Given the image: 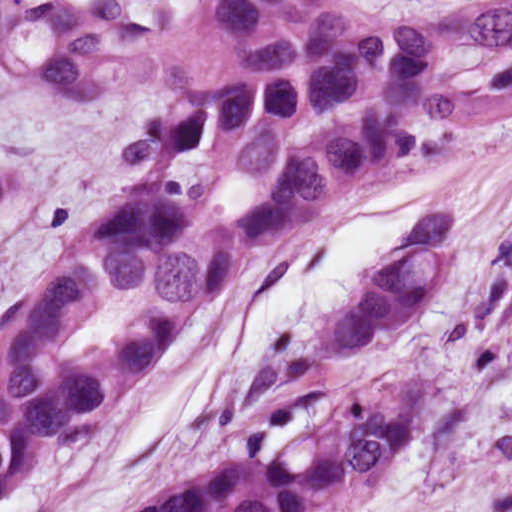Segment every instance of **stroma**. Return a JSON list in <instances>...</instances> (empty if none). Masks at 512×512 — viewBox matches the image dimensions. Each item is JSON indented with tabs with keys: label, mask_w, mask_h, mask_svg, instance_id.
<instances>
[{
	"label": "stroma",
	"mask_w": 512,
	"mask_h": 512,
	"mask_svg": "<svg viewBox=\"0 0 512 512\" xmlns=\"http://www.w3.org/2000/svg\"><path fill=\"white\" fill-rule=\"evenodd\" d=\"M388 17L475 0H368ZM452 213L445 286L358 353L324 324L376 283L433 207ZM405 375V376H404ZM421 385L382 487L345 512H443L512 480V126L385 165L250 269L182 358L114 403L0 512H124L173 479L284 457L338 395Z\"/></svg>",
	"instance_id": "1"
}]
</instances>
